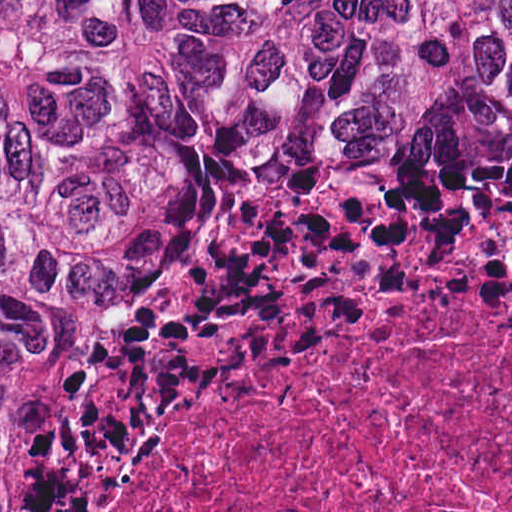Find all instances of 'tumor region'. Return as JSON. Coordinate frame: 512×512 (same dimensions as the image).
Here are the masks:
<instances>
[{"label": "tumor region", "mask_w": 512, "mask_h": 512, "mask_svg": "<svg viewBox=\"0 0 512 512\" xmlns=\"http://www.w3.org/2000/svg\"><path fill=\"white\" fill-rule=\"evenodd\" d=\"M407 281H512V0H0V512H137Z\"/></svg>", "instance_id": "e687c5a6"}]
</instances>
